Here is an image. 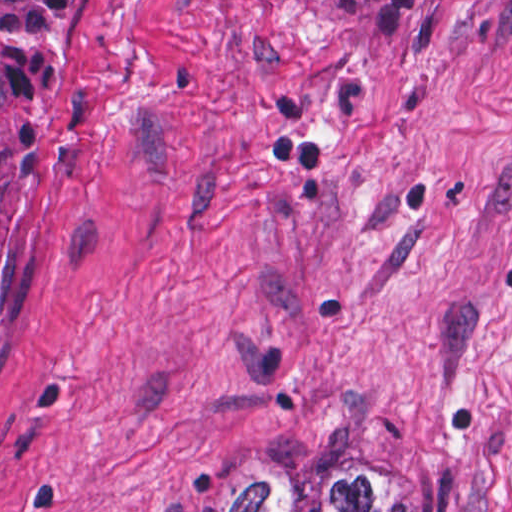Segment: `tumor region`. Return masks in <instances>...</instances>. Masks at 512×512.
Returning <instances> with one entry per match:
<instances>
[{
  "mask_svg": "<svg viewBox=\"0 0 512 512\" xmlns=\"http://www.w3.org/2000/svg\"><path fill=\"white\" fill-rule=\"evenodd\" d=\"M81 1H0V330L43 176V95ZM154 512H432L405 482L319 468L227 496H176ZM490 512H512V470Z\"/></svg>",
  "mask_w": 512,
  "mask_h": 512,
  "instance_id": "obj_1",
  "label": "tumor region"
}]
</instances>
